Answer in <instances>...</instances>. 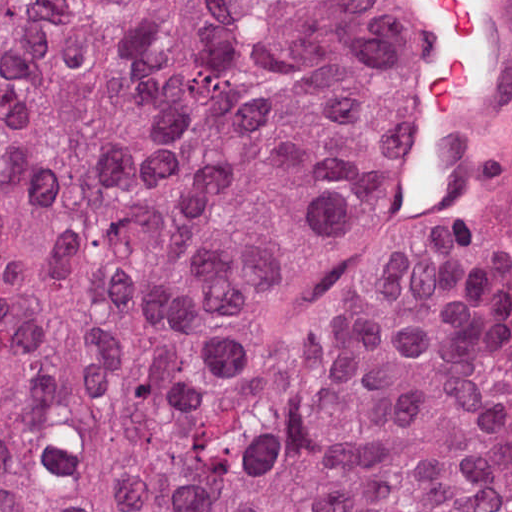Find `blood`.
I'll use <instances>...</instances> for the list:
<instances>
[{"mask_svg": "<svg viewBox=\"0 0 512 512\" xmlns=\"http://www.w3.org/2000/svg\"><path fill=\"white\" fill-rule=\"evenodd\" d=\"M453 17L445 46L421 99L432 124H459L473 82L470 53L476 23V0H437Z\"/></svg>", "mask_w": 512, "mask_h": 512, "instance_id": "1a1defca", "label": "blood"}]
</instances>
